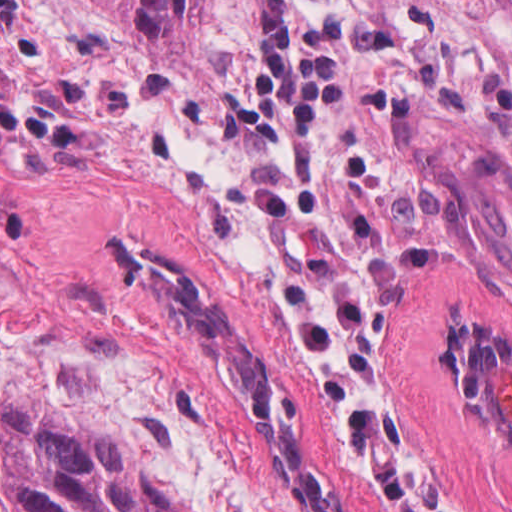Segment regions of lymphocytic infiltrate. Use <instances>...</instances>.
<instances>
[{"label":"lymphocytic infiltrate","mask_w":512,"mask_h":512,"mask_svg":"<svg viewBox=\"0 0 512 512\" xmlns=\"http://www.w3.org/2000/svg\"><path fill=\"white\" fill-rule=\"evenodd\" d=\"M249 75L232 114L275 148L289 133L297 153L311 148L316 127L347 97V58L324 40L320 22L293 21L286 0L259 1ZM393 417L363 403L344 423L343 444L386 512H429L394 446Z\"/></svg>","instance_id":"lymphocytic-infiltrate-1"}]
</instances>
